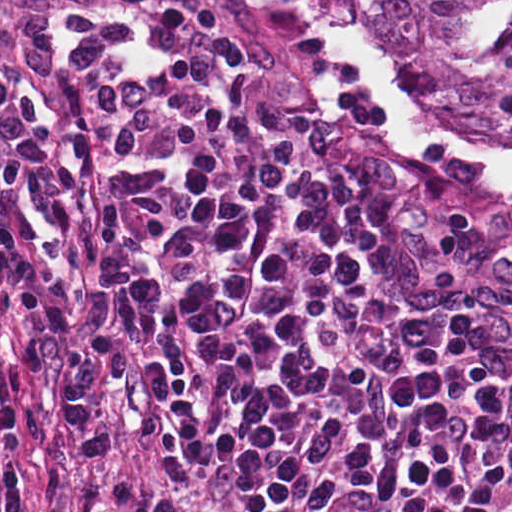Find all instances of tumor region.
Instances as JSON below:
<instances>
[{
    "label": "tumor region",
    "instance_id": "1",
    "mask_svg": "<svg viewBox=\"0 0 512 512\" xmlns=\"http://www.w3.org/2000/svg\"><path fill=\"white\" fill-rule=\"evenodd\" d=\"M372 73L512 79V0H331Z\"/></svg>",
    "mask_w": 512,
    "mask_h": 512
}]
</instances>
